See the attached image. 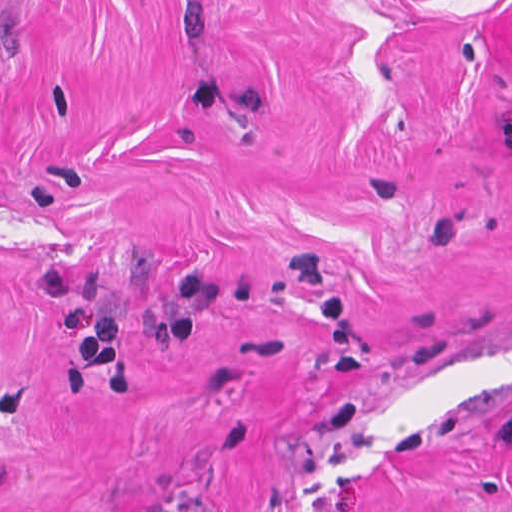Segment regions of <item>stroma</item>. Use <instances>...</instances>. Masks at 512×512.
Returning a JSON list of instances; mask_svg holds the SVG:
<instances>
[{
    "label": "stroma",
    "instance_id": "35a3bbf8",
    "mask_svg": "<svg viewBox=\"0 0 512 512\" xmlns=\"http://www.w3.org/2000/svg\"><path fill=\"white\" fill-rule=\"evenodd\" d=\"M512 0H0V512H512Z\"/></svg>",
    "mask_w": 512,
    "mask_h": 512
}]
</instances>
